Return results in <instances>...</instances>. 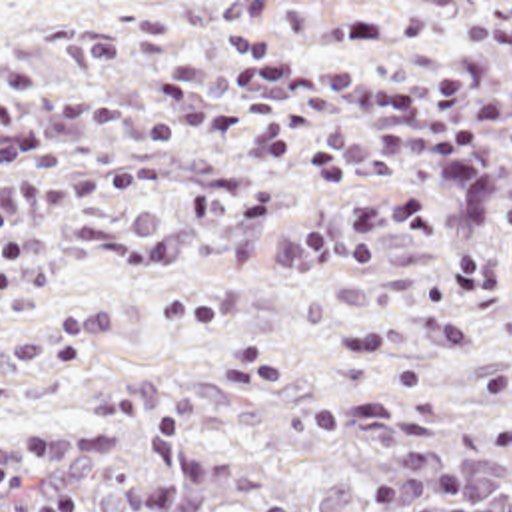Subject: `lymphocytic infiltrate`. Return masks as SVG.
Segmentation results:
<instances>
[{
  "instance_id": "f902f5d3",
  "label": "lymphocytic infiltrate",
  "mask_w": 512,
  "mask_h": 512,
  "mask_svg": "<svg viewBox=\"0 0 512 512\" xmlns=\"http://www.w3.org/2000/svg\"><path fill=\"white\" fill-rule=\"evenodd\" d=\"M483 433L497 451L512 453V417L489 419Z\"/></svg>"
}]
</instances>
